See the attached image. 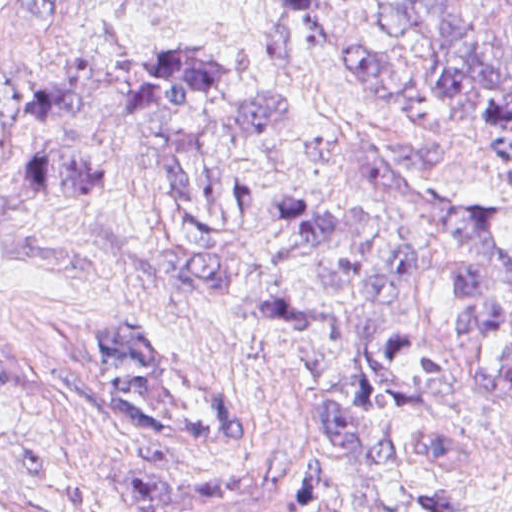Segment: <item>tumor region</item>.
<instances>
[{"instance_id":"1","label":"tumor region","mask_w":512,"mask_h":512,"mask_svg":"<svg viewBox=\"0 0 512 512\" xmlns=\"http://www.w3.org/2000/svg\"><path fill=\"white\" fill-rule=\"evenodd\" d=\"M355 72L488 137L512 193V0H385ZM311 99L99 54L0 126V236L194 286L296 360L326 433L388 463L479 459L512 375V241L450 217ZM134 512H343L267 473H151ZM0 512H36L0 495Z\"/></svg>"}]
</instances>
